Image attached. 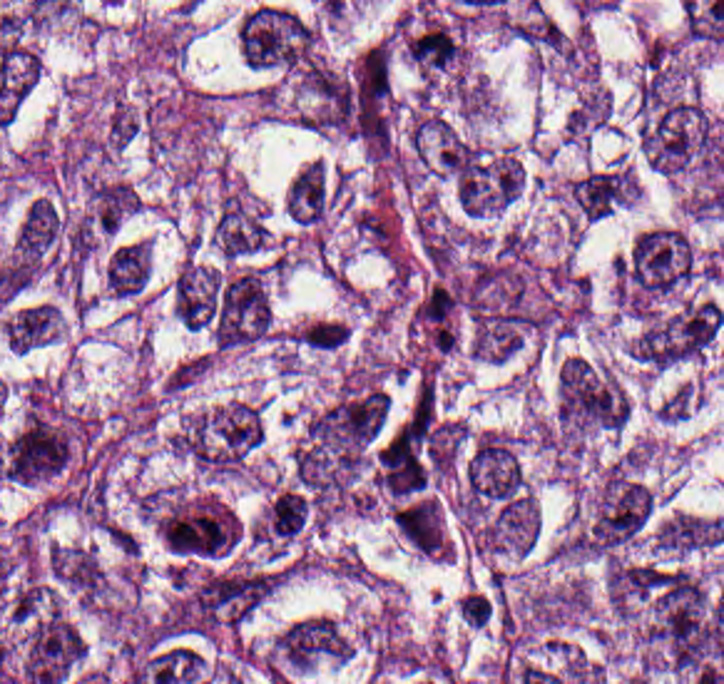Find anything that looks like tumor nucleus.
I'll return each instance as SVG.
<instances>
[{
    "mask_svg": "<svg viewBox=\"0 0 724 684\" xmlns=\"http://www.w3.org/2000/svg\"><path fill=\"white\" fill-rule=\"evenodd\" d=\"M654 499L643 462L619 455L594 480L570 534L571 550L613 558L653 521Z\"/></svg>",
    "mask_w": 724,
    "mask_h": 684,
    "instance_id": "obj_1",
    "label": "tumor nucleus"
},
{
    "mask_svg": "<svg viewBox=\"0 0 724 684\" xmlns=\"http://www.w3.org/2000/svg\"><path fill=\"white\" fill-rule=\"evenodd\" d=\"M263 437L257 403L228 400L184 418L169 441L194 471L229 476L253 460Z\"/></svg>",
    "mask_w": 724,
    "mask_h": 684,
    "instance_id": "obj_2",
    "label": "tumor nucleus"
},
{
    "mask_svg": "<svg viewBox=\"0 0 724 684\" xmlns=\"http://www.w3.org/2000/svg\"><path fill=\"white\" fill-rule=\"evenodd\" d=\"M628 420V393L616 378L580 355H567L557 379V424L583 438L613 431Z\"/></svg>",
    "mask_w": 724,
    "mask_h": 684,
    "instance_id": "obj_3",
    "label": "tumor nucleus"
},
{
    "mask_svg": "<svg viewBox=\"0 0 724 684\" xmlns=\"http://www.w3.org/2000/svg\"><path fill=\"white\" fill-rule=\"evenodd\" d=\"M238 49L248 68L289 73L309 56L307 17L267 2L253 7L238 22Z\"/></svg>",
    "mask_w": 724,
    "mask_h": 684,
    "instance_id": "obj_4",
    "label": "tumor nucleus"
},
{
    "mask_svg": "<svg viewBox=\"0 0 724 684\" xmlns=\"http://www.w3.org/2000/svg\"><path fill=\"white\" fill-rule=\"evenodd\" d=\"M47 580L84 608H100L110 586L105 567L90 545L53 543Z\"/></svg>",
    "mask_w": 724,
    "mask_h": 684,
    "instance_id": "obj_5",
    "label": "tumor nucleus"
},
{
    "mask_svg": "<svg viewBox=\"0 0 724 684\" xmlns=\"http://www.w3.org/2000/svg\"><path fill=\"white\" fill-rule=\"evenodd\" d=\"M137 191L120 179L94 176L87 184L84 224L89 232H115L139 206Z\"/></svg>",
    "mask_w": 724,
    "mask_h": 684,
    "instance_id": "obj_6",
    "label": "tumor nucleus"
},
{
    "mask_svg": "<svg viewBox=\"0 0 724 684\" xmlns=\"http://www.w3.org/2000/svg\"><path fill=\"white\" fill-rule=\"evenodd\" d=\"M59 325L60 311L53 303L27 298L2 316V340L12 351H28L53 339Z\"/></svg>",
    "mask_w": 724,
    "mask_h": 684,
    "instance_id": "obj_7",
    "label": "tumor nucleus"
},
{
    "mask_svg": "<svg viewBox=\"0 0 724 684\" xmlns=\"http://www.w3.org/2000/svg\"><path fill=\"white\" fill-rule=\"evenodd\" d=\"M146 286L145 243L124 238L104 256V290L116 299H140Z\"/></svg>",
    "mask_w": 724,
    "mask_h": 684,
    "instance_id": "obj_8",
    "label": "tumor nucleus"
},
{
    "mask_svg": "<svg viewBox=\"0 0 724 684\" xmlns=\"http://www.w3.org/2000/svg\"><path fill=\"white\" fill-rule=\"evenodd\" d=\"M610 99L603 89L591 87L568 111L565 118L567 145H583L606 123Z\"/></svg>",
    "mask_w": 724,
    "mask_h": 684,
    "instance_id": "obj_9",
    "label": "tumor nucleus"
}]
</instances>
